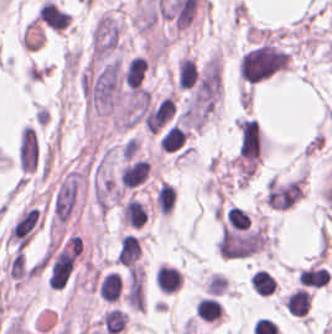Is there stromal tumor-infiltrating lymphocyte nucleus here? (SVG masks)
Listing matches in <instances>:
<instances>
[{"label": "stromal tumor-infiltrating lymphocyte nucleus", "mask_w": 332, "mask_h": 334, "mask_svg": "<svg viewBox=\"0 0 332 334\" xmlns=\"http://www.w3.org/2000/svg\"><path fill=\"white\" fill-rule=\"evenodd\" d=\"M250 284L256 294L272 295L276 290V279L265 268H257L250 275Z\"/></svg>", "instance_id": "3290ff9b"}, {"label": "stromal tumor-infiltrating lymphocyte nucleus", "mask_w": 332, "mask_h": 334, "mask_svg": "<svg viewBox=\"0 0 332 334\" xmlns=\"http://www.w3.org/2000/svg\"><path fill=\"white\" fill-rule=\"evenodd\" d=\"M122 282L115 272H107L100 281L99 290L102 300L115 302L121 293Z\"/></svg>", "instance_id": "9ea309e8"}, {"label": "stromal tumor-infiltrating lymphocyte nucleus", "mask_w": 332, "mask_h": 334, "mask_svg": "<svg viewBox=\"0 0 332 334\" xmlns=\"http://www.w3.org/2000/svg\"><path fill=\"white\" fill-rule=\"evenodd\" d=\"M156 285L163 291L175 292L177 291L183 282V272L173 266L166 264H160L156 268L155 274Z\"/></svg>", "instance_id": "52c7bb5b"}, {"label": "stromal tumor-infiltrating lymphocyte nucleus", "mask_w": 332, "mask_h": 334, "mask_svg": "<svg viewBox=\"0 0 332 334\" xmlns=\"http://www.w3.org/2000/svg\"><path fill=\"white\" fill-rule=\"evenodd\" d=\"M101 321L104 329L112 334L122 331L127 321L126 311L109 309L101 315Z\"/></svg>", "instance_id": "f3e2335f"}, {"label": "stromal tumor-infiltrating lymphocyte nucleus", "mask_w": 332, "mask_h": 334, "mask_svg": "<svg viewBox=\"0 0 332 334\" xmlns=\"http://www.w3.org/2000/svg\"><path fill=\"white\" fill-rule=\"evenodd\" d=\"M195 314L199 319L219 320L222 314V305L218 298L202 297L195 303Z\"/></svg>", "instance_id": "abfb95fc"}, {"label": "stromal tumor-infiltrating lymphocyte nucleus", "mask_w": 332, "mask_h": 334, "mask_svg": "<svg viewBox=\"0 0 332 334\" xmlns=\"http://www.w3.org/2000/svg\"><path fill=\"white\" fill-rule=\"evenodd\" d=\"M149 172V161L137 158L123 166L120 173L121 186L133 188L144 182Z\"/></svg>", "instance_id": "bc302bb0"}]
</instances>
